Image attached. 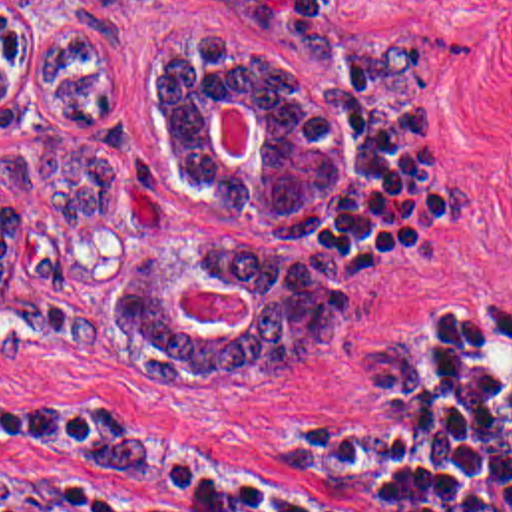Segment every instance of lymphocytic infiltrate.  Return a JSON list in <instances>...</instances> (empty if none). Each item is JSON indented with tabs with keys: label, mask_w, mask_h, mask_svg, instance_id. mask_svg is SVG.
<instances>
[{
	"label": "lymphocytic infiltrate",
	"mask_w": 512,
	"mask_h": 512,
	"mask_svg": "<svg viewBox=\"0 0 512 512\" xmlns=\"http://www.w3.org/2000/svg\"><path fill=\"white\" fill-rule=\"evenodd\" d=\"M0 512H512V292L369 322L363 437L284 493L164 511L71 479H0Z\"/></svg>",
	"instance_id": "lymphocytic-infiltrate-1"
}]
</instances>
